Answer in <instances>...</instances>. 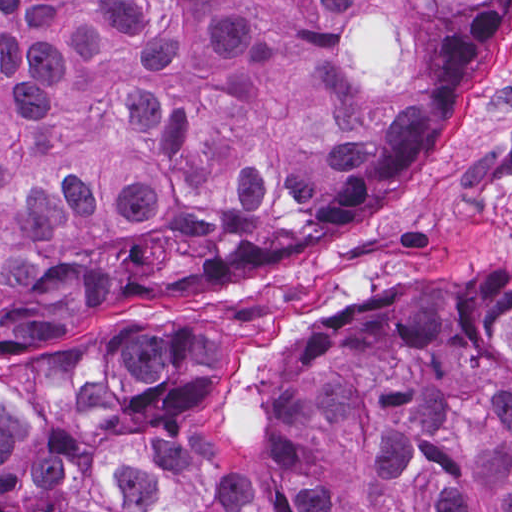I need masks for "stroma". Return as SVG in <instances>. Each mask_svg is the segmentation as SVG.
Returning a JSON list of instances; mask_svg holds the SVG:
<instances>
[{"label": "stroma", "mask_w": 512, "mask_h": 512, "mask_svg": "<svg viewBox=\"0 0 512 512\" xmlns=\"http://www.w3.org/2000/svg\"><path fill=\"white\" fill-rule=\"evenodd\" d=\"M510 259L512 14L367 220L226 294L89 311L37 351L0 359V396L79 401L140 344L192 361L210 383L282 370L393 276L488 280Z\"/></svg>", "instance_id": "1"}]
</instances>
